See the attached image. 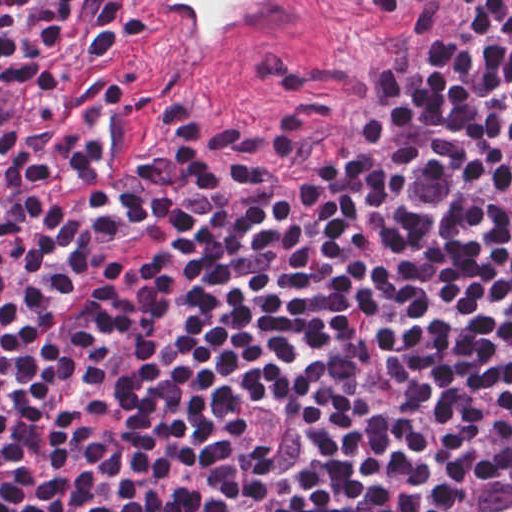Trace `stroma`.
<instances>
[{"instance_id": "obj_1", "label": "stroma", "mask_w": 512, "mask_h": 512, "mask_svg": "<svg viewBox=\"0 0 512 512\" xmlns=\"http://www.w3.org/2000/svg\"><path fill=\"white\" fill-rule=\"evenodd\" d=\"M120 57L147 97V141L165 158L207 124L238 127L268 151L296 117L317 110L351 63L353 47L342 22L335 44L315 62L287 77L220 84L142 46L108 11Z\"/></svg>"}]
</instances>
